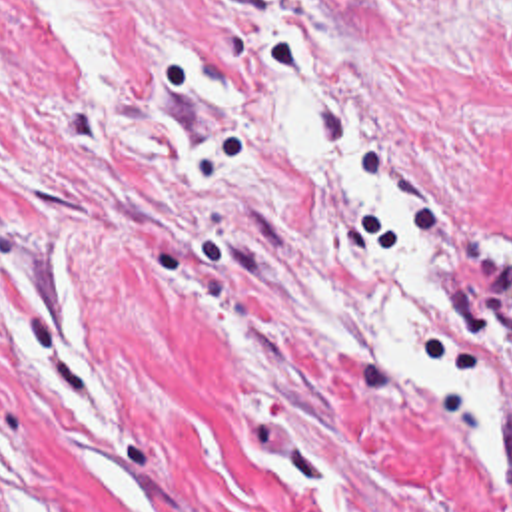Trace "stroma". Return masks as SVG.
<instances>
[{
	"mask_svg": "<svg viewBox=\"0 0 512 512\" xmlns=\"http://www.w3.org/2000/svg\"><path fill=\"white\" fill-rule=\"evenodd\" d=\"M295 83L437 239L431 353L512 386V0H0V512H138L34 343L56 251L150 512H512L471 426L383 359L391 243L287 157Z\"/></svg>",
	"mask_w": 512,
	"mask_h": 512,
	"instance_id": "obj_1",
	"label": "stroma"
}]
</instances>
